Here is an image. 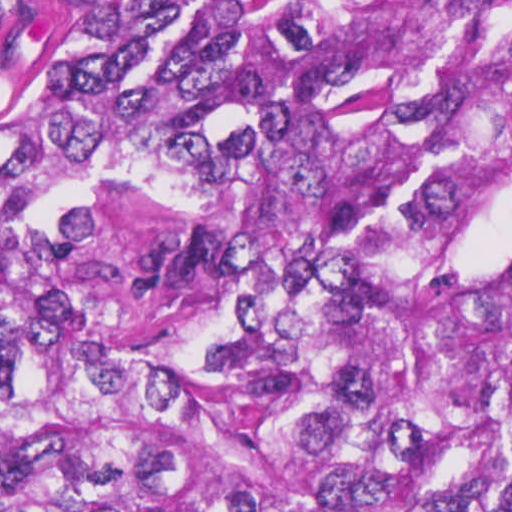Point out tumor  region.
I'll return each instance as SVG.
<instances>
[{
    "label": "tumor region",
    "mask_w": 512,
    "mask_h": 512,
    "mask_svg": "<svg viewBox=\"0 0 512 512\" xmlns=\"http://www.w3.org/2000/svg\"><path fill=\"white\" fill-rule=\"evenodd\" d=\"M0 512H512V0H0Z\"/></svg>",
    "instance_id": "1"
}]
</instances>
